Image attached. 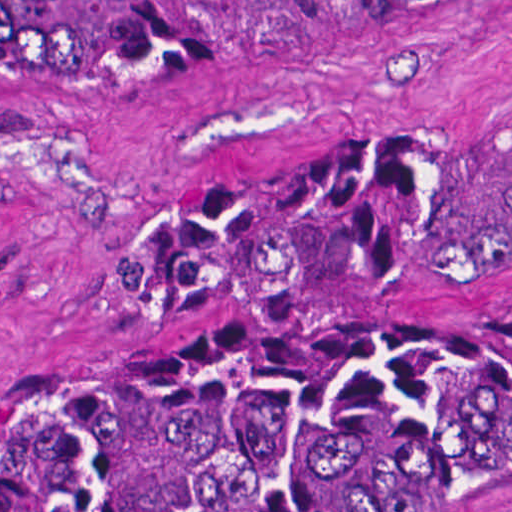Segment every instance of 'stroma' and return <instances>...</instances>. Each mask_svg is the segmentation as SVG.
<instances>
[{"label":"stroma","instance_id":"stroma-1","mask_svg":"<svg viewBox=\"0 0 512 512\" xmlns=\"http://www.w3.org/2000/svg\"><path fill=\"white\" fill-rule=\"evenodd\" d=\"M512 108V0L320 54L192 76H0V413L36 391L267 324L331 315L512 323V280L272 322H139L126 253L306 152ZM368 512H512V432Z\"/></svg>","mask_w":512,"mask_h":512}]
</instances>
